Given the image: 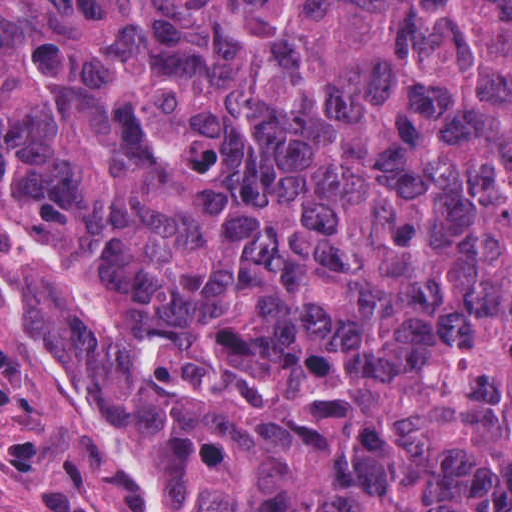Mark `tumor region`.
Masks as SVG:
<instances>
[{"label": "tumor region", "instance_id": "e687c5a6", "mask_svg": "<svg viewBox=\"0 0 512 512\" xmlns=\"http://www.w3.org/2000/svg\"><path fill=\"white\" fill-rule=\"evenodd\" d=\"M0 228L162 512H512V0H0Z\"/></svg>", "mask_w": 512, "mask_h": 512}]
</instances>
